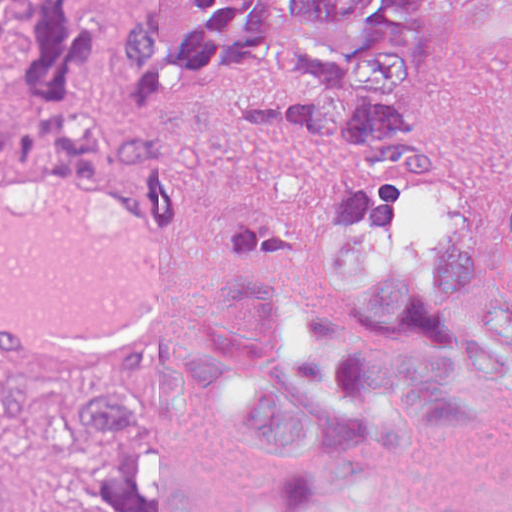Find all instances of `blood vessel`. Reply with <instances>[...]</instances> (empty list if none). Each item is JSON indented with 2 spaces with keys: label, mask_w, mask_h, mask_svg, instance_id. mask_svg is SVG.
<instances>
[{
  "label": "blood vessel",
  "mask_w": 512,
  "mask_h": 512,
  "mask_svg": "<svg viewBox=\"0 0 512 512\" xmlns=\"http://www.w3.org/2000/svg\"><path fill=\"white\" fill-rule=\"evenodd\" d=\"M142 173L0 177V376L166 341L209 309L193 216Z\"/></svg>",
  "instance_id": "8fb6f2fc"
}]
</instances>
